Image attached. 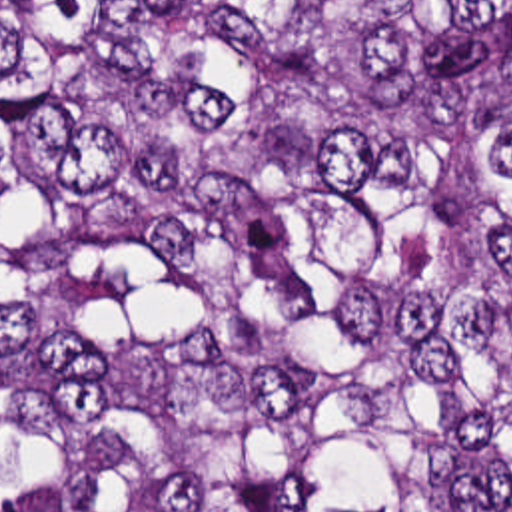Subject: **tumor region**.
<instances>
[{"mask_svg": "<svg viewBox=\"0 0 512 512\" xmlns=\"http://www.w3.org/2000/svg\"><path fill=\"white\" fill-rule=\"evenodd\" d=\"M0 512H512V0H0Z\"/></svg>", "mask_w": 512, "mask_h": 512, "instance_id": "e687c5a6", "label": "tumor region"}]
</instances>
